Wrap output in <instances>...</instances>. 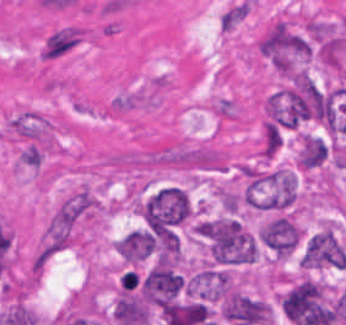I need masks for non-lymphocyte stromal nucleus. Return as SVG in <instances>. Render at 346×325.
Returning a JSON list of instances; mask_svg holds the SVG:
<instances>
[{
	"instance_id": "obj_1",
	"label": "non-lymphocyte stromal nucleus",
	"mask_w": 346,
	"mask_h": 325,
	"mask_svg": "<svg viewBox=\"0 0 346 325\" xmlns=\"http://www.w3.org/2000/svg\"><path fill=\"white\" fill-rule=\"evenodd\" d=\"M167 87V79L152 75L115 94L106 105V111L124 113L156 106Z\"/></svg>"
},
{
	"instance_id": "obj_2",
	"label": "non-lymphocyte stromal nucleus",
	"mask_w": 346,
	"mask_h": 325,
	"mask_svg": "<svg viewBox=\"0 0 346 325\" xmlns=\"http://www.w3.org/2000/svg\"><path fill=\"white\" fill-rule=\"evenodd\" d=\"M85 26L64 24L51 30L41 46V58L54 60L69 54L84 41Z\"/></svg>"
},
{
	"instance_id": "obj_3",
	"label": "non-lymphocyte stromal nucleus",
	"mask_w": 346,
	"mask_h": 325,
	"mask_svg": "<svg viewBox=\"0 0 346 325\" xmlns=\"http://www.w3.org/2000/svg\"><path fill=\"white\" fill-rule=\"evenodd\" d=\"M247 11L248 3L241 0L233 4L219 18L222 29L229 31L247 14Z\"/></svg>"
}]
</instances>
